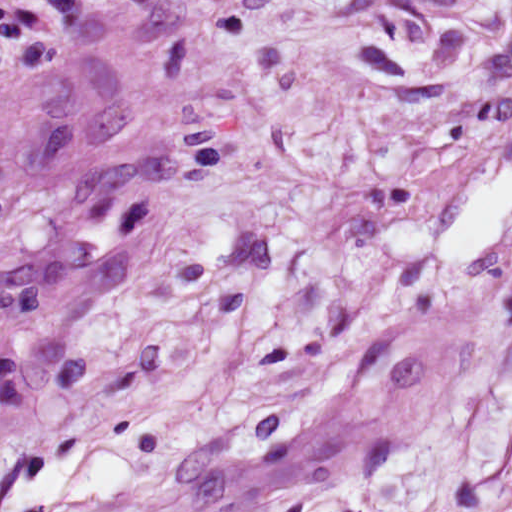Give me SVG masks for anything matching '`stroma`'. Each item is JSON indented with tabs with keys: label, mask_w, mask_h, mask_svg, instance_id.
Segmentation results:
<instances>
[{
	"label": "stroma",
	"mask_w": 512,
	"mask_h": 512,
	"mask_svg": "<svg viewBox=\"0 0 512 512\" xmlns=\"http://www.w3.org/2000/svg\"><path fill=\"white\" fill-rule=\"evenodd\" d=\"M296 512H512V0H68Z\"/></svg>",
	"instance_id": "35a3bbf8"
}]
</instances>
